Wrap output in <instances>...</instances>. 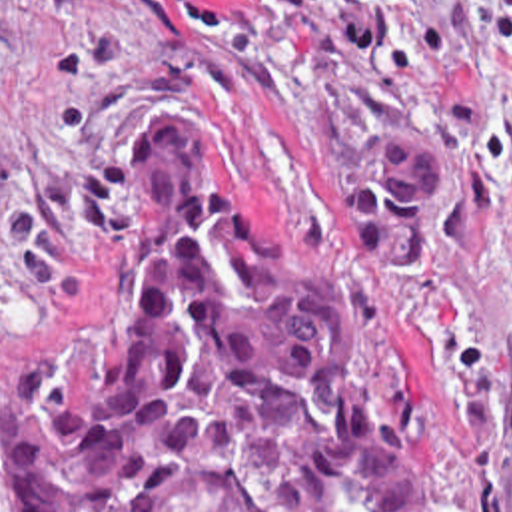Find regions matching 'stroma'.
Listing matches in <instances>:
<instances>
[{
	"label": "stroma",
	"instance_id": "obj_1",
	"mask_svg": "<svg viewBox=\"0 0 512 512\" xmlns=\"http://www.w3.org/2000/svg\"><path fill=\"white\" fill-rule=\"evenodd\" d=\"M365 0H0V384L108 264L134 147L194 119L263 244L367 298L383 384L451 512H512V47L395 79L337 55ZM401 25L465 0H389ZM373 137L441 155L417 250L375 258L349 198ZM0 512H16L0 500Z\"/></svg>",
	"mask_w": 512,
	"mask_h": 512
}]
</instances>
